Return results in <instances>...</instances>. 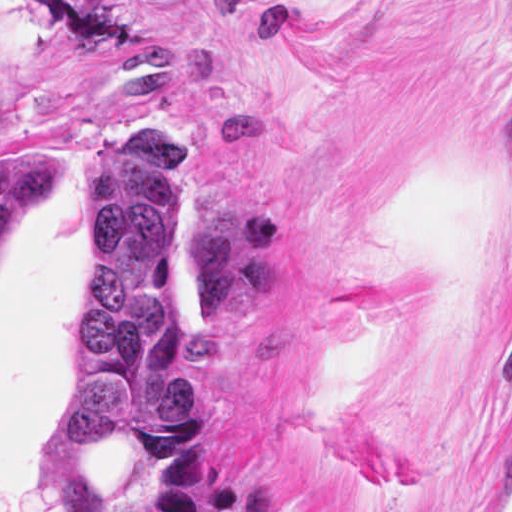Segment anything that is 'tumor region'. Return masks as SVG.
<instances>
[{"label":"tumor region","mask_w":512,"mask_h":512,"mask_svg":"<svg viewBox=\"0 0 512 512\" xmlns=\"http://www.w3.org/2000/svg\"><path fill=\"white\" fill-rule=\"evenodd\" d=\"M50 178V160L10 151L0 96V242ZM184 217L182 156L155 123L137 119L86 174V267L65 338L74 417L39 465L53 512H140L96 498V462L121 437L191 409V373L171 344Z\"/></svg>","instance_id":"e687c5a6"}]
</instances>
